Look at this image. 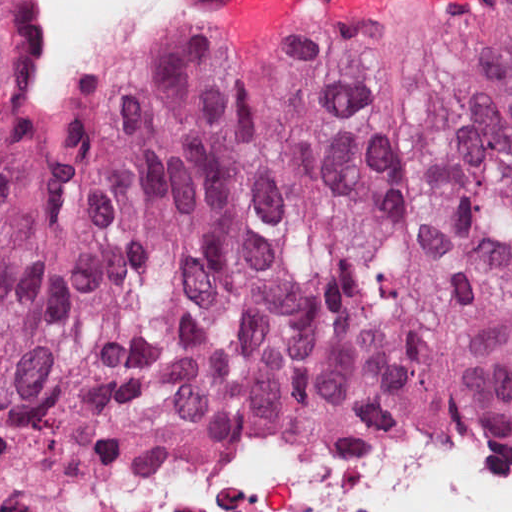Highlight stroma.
Wrapping results in <instances>:
<instances>
[{"label":"stroma","instance_id":"stroma-1","mask_svg":"<svg viewBox=\"0 0 512 512\" xmlns=\"http://www.w3.org/2000/svg\"><path fill=\"white\" fill-rule=\"evenodd\" d=\"M0 3H5V0H0ZM312 25L262 34L256 42H237L245 49L262 52L296 30ZM143 47L121 64L98 76L123 71ZM21 135L14 136V111L4 64L0 72V151L12 145ZM229 427L273 430L258 416L230 414L153 432L55 473L36 463L17 431L0 425V509H32L26 512H97L88 496L90 485L107 475L168 450L176 441Z\"/></svg>","mask_w":512,"mask_h":512}]
</instances>
